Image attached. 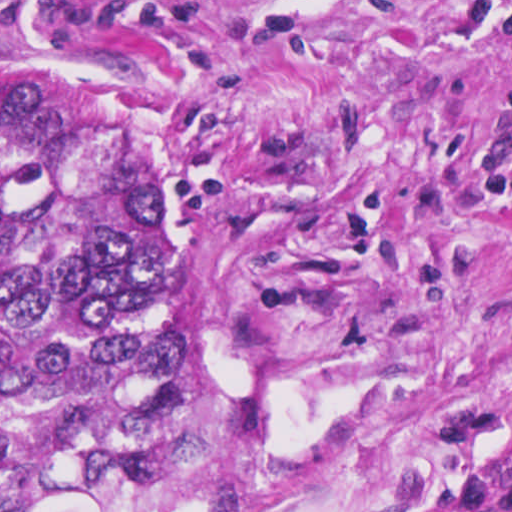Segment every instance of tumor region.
Masks as SVG:
<instances>
[{"label": "tumor region", "mask_w": 512, "mask_h": 512, "mask_svg": "<svg viewBox=\"0 0 512 512\" xmlns=\"http://www.w3.org/2000/svg\"><path fill=\"white\" fill-rule=\"evenodd\" d=\"M176 414V221L153 158L0 91V512L138 482Z\"/></svg>", "instance_id": "obj_1"}]
</instances>
